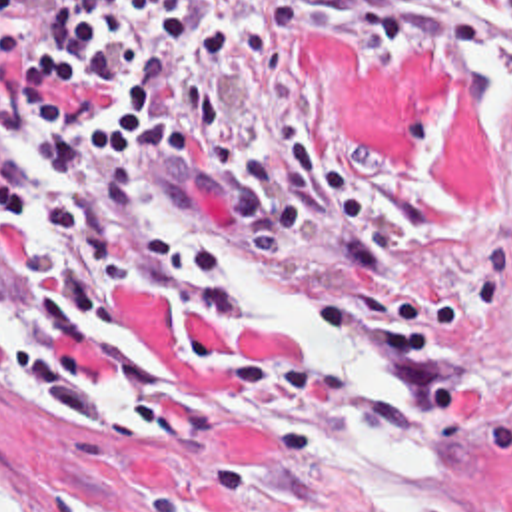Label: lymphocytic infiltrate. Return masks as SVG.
I'll list each match as a JSON object with an SVG mask.
<instances>
[{"instance_id":"lymphocytic-infiltrate-1","label":"lymphocytic infiltrate","mask_w":512,"mask_h":512,"mask_svg":"<svg viewBox=\"0 0 512 512\" xmlns=\"http://www.w3.org/2000/svg\"><path fill=\"white\" fill-rule=\"evenodd\" d=\"M292 21L368 43L443 37L512 75V0H70L44 23L0 17V57H16L0 123L58 177V191L24 197L0 173V201L36 207L54 235L50 253L38 243L30 253L36 341L22 359L76 425L100 421L86 353L114 287L226 315V259L142 213L138 187L172 157L214 151L228 161L232 215L258 249L298 239L340 267L376 271L368 225L320 195L366 215L368 191L298 115H270L260 147L230 143V99L310 93L308 47Z\"/></svg>"}]
</instances>
